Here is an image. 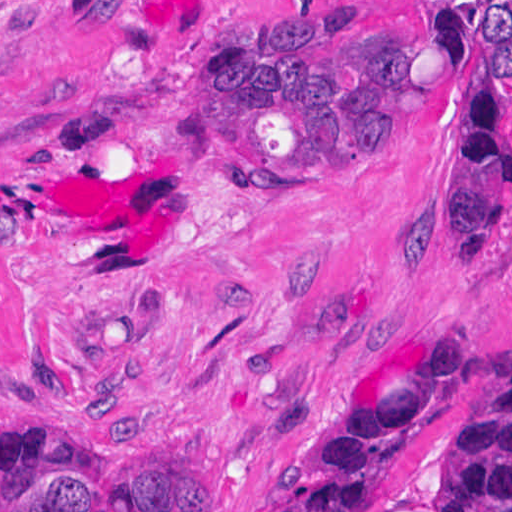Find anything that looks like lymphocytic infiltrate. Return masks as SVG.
Instances as JSON below:
<instances>
[{"label": "lymphocytic infiltrate", "instance_id": "f902f5d3", "mask_svg": "<svg viewBox=\"0 0 512 512\" xmlns=\"http://www.w3.org/2000/svg\"><path fill=\"white\" fill-rule=\"evenodd\" d=\"M475 33L467 56L512 75V1H468ZM455 109L469 128V154L443 232H483L512 201V138L493 98L463 100Z\"/></svg>", "mask_w": 512, "mask_h": 512}]
</instances>
